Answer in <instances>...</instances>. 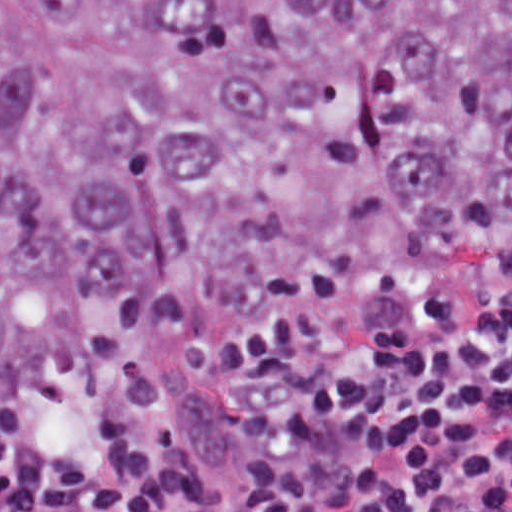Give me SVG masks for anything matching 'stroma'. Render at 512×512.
I'll use <instances>...</instances> for the list:
<instances>
[{"label": "stroma", "instance_id": "stroma-1", "mask_svg": "<svg viewBox=\"0 0 512 512\" xmlns=\"http://www.w3.org/2000/svg\"><path fill=\"white\" fill-rule=\"evenodd\" d=\"M507 303H512V294L428 296L374 306L350 315H395L436 306H496ZM292 330L245 338L171 343L146 357L34 382L2 406L0 412L35 403H94L159 377L200 376L220 366L245 362Z\"/></svg>", "mask_w": 512, "mask_h": 512}]
</instances>
